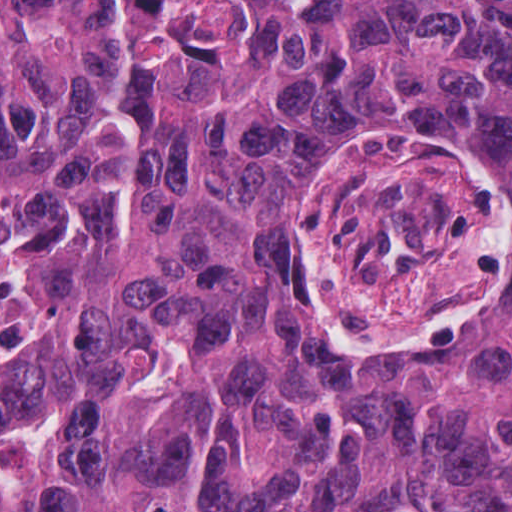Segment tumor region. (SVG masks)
Returning a JSON list of instances; mask_svg holds the SVG:
<instances>
[{
    "mask_svg": "<svg viewBox=\"0 0 512 512\" xmlns=\"http://www.w3.org/2000/svg\"><path fill=\"white\" fill-rule=\"evenodd\" d=\"M0 512H512V0H0Z\"/></svg>",
    "mask_w": 512,
    "mask_h": 512,
    "instance_id": "obj_1",
    "label": "tumor region"
}]
</instances>
